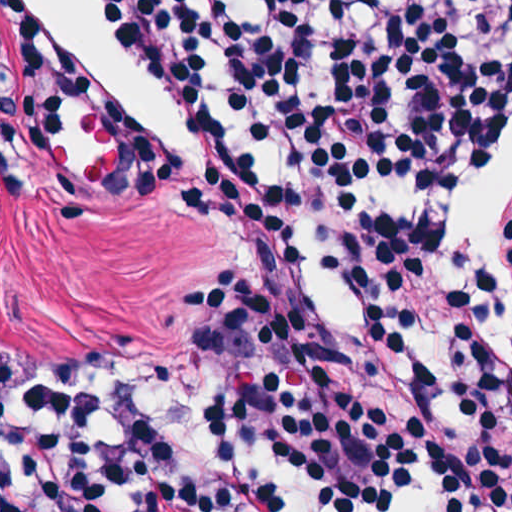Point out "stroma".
<instances>
[{
	"instance_id": "35a3bbf8",
	"label": "stroma",
	"mask_w": 512,
	"mask_h": 512,
	"mask_svg": "<svg viewBox=\"0 0 512 512\" xmlns=\"http://www.w3.org/2000/svg\"><path fill=\"white\" fill-rule=\"evenodd\" d=\"M41 1L119 88L128 134L105 135L69 110L47 149L22 146L1 54L0 0V512L1 409L22 373L114 347L137 365L129 405L214 403L187 341L184 289L214 270L248 275L252 267L240 232L207 217L186 218L162 204L107 203V182L132 140L192 163L215 144L188 140L207 135L184 134L178 114L138 81L81 0ZM506 352L512 362V253Z\"/></svg>"
}]
</instances>
